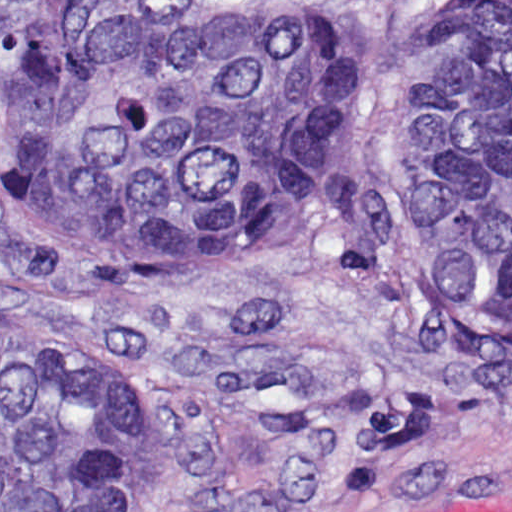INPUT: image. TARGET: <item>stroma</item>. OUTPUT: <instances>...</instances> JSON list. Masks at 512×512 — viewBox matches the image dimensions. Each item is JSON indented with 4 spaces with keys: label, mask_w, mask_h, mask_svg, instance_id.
<instances>
[{
    "label": "stroma",
    "mask_w": 512,
    "mask_h": 512,
    "mask_svg": "<svg viewBox=\"0 0 512 512\" xmlns=\"http://www.w3.org/2000/svg\"><path fill=\"white\" fill-rule=\"evenodd\" d=\"M185 1L199 20H383L400 64L321 215L279 242L60 272L0 193V335L124 353L135 512H512V327L416 303L394 240V106L438 0Z\"/></svg>",
    "instance_id": "obj_1"
}]
</instances>
